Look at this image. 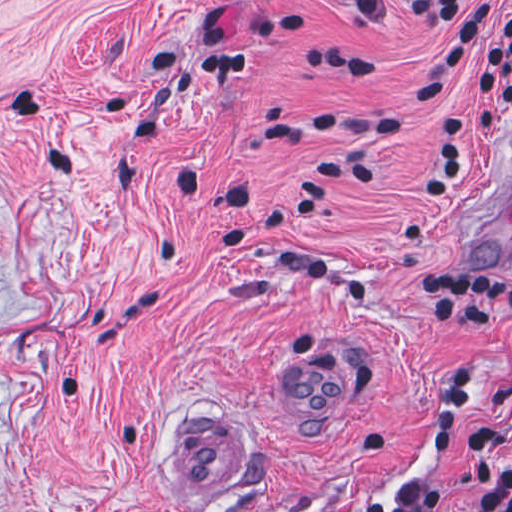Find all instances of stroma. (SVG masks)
Masks as SVG:
<instances>
[{
    "label": "stroma",
    "instance_id": "obj_1",
    "mask_svg": "<svg viewBox=\"0 0 512 512\" xmlns=\"http://www.w3.org/2000/svg\"><path fill=\"white\" fill-rule=\"evenodd\" d=\"M208 23L249 66L201 72ZM456 24L372 28L340 0H0V512H357L376 493L400 508L421 478L439 512H463L476 430L512 468V329L428 331L413 301L432 263L512 277V243L482 262L447 249L512 114L469 141L449 200H421L441 116L478 103L476 40L450 88L381 146L252 135L300 104L397 109ZM302 46L370 59L374 74L307 67ZM332 156L375 179L248 230L328 257V276L217 243L230 189L252 187L248 217ZM300 339L358 366V402L333 432H300L280 406V358ZM466 344L475 384L450 437L437 411ZM202 405L236 425L224 489L179 502L163 450L178 413ZM448 439L441 457L416 455Z\"/></svg>",
    "mask_w": 512,
    "mask_h": 512
}]
</instances>
